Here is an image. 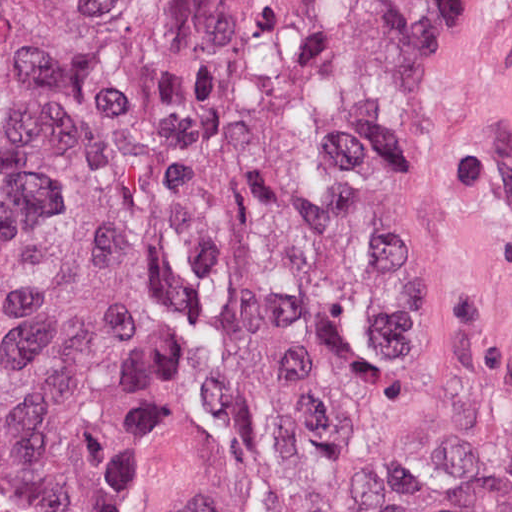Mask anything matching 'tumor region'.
<instances>
[{
	"label": "tumor region",
	"instance_id": "obj_1",
	"mask_svg": "<svg viewBox=\"0 0 512 512\" xmlns=\"http://www.w3.org/2000/svg\"><path fill=\"white\" fill-rule=\"evenodd\" d=\"M459 1L0 0V512H117L151 264L152 512H512L416 259Z\"/></svg>",
	"mask_w": 512,
	"mask_h": 512
}]
</instances>
